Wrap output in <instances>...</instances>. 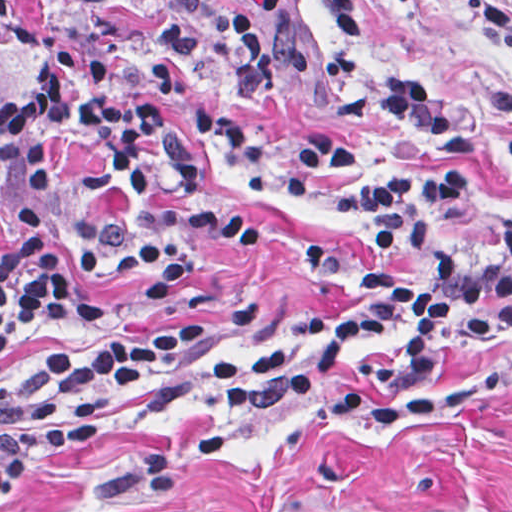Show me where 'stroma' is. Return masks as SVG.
Masks as SVG:
<instances>
[{
    "label": "stroma",
    "instance_id": "1",
    "mask_svg": "<svg viewBox=\"0 0 512 512\" xmlns=\"http://www.w3.org/2000/svg\"><path fill=\"white\" fill-rule=\"evenodd\" d=\"M227 1V0H221ZM321 41L327 83L397 60L427 82L460 131L440 148L370 107L304 109L253 93L247 113L270 157L316 134L339 135L337 172L286 188L276 215L248 231L199 281L196 298L160 300L130 277L85 262L63 225L79 287L107 305L87 325L33 332L0 356V393L51 352H82L183 328L218 326L206 357L232 383L247 357L303 318L358 311L331 251L369 257L337 211L339 179L359 169L451 164L512 199V56L462 0H359L353 40L317 0H297ZM512 13V0H502ZM79 0H13L0 10V104L38 78L45 47L83 37ZM77 457L0 512H512V337L375 395L346 401H126Z\"/></svg>",
    "mask_w": 512,
    "mask_h": 512
}]
</instances>
